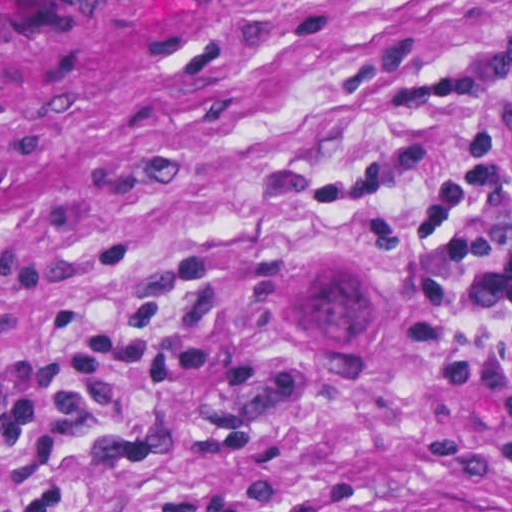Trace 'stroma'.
<instances>
[{
  "instance_id": "1",
  "label": "stroma",
  "mask_w": 512,
  "mask_h": 512,
  "mask_svg": "<svg viewBox=\"0 0 512 512\" xmlns=\"http://www.w3.org/2000/svg\"><path fill=\"white\" fill-rule=\"evenodd\" d=\"M406 52L485 87L396 206L512 162V0H0V512H512L324 186Z\"/></svg>"
}]
</instances>
